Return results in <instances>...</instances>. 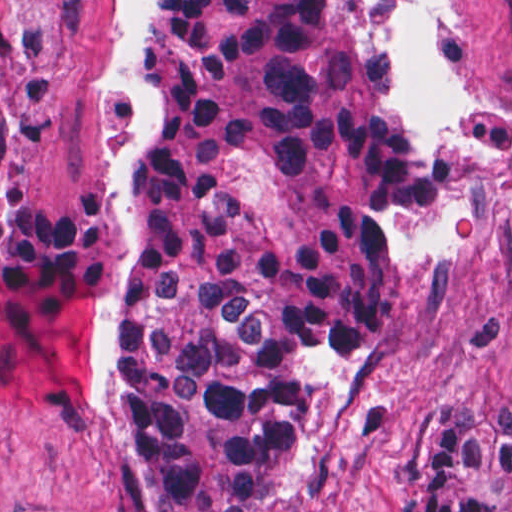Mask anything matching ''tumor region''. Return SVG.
I'll return each mask as SVG.
<instances>
[{
	"instance_id": "e687c5a6",
	"label": "tumor region",
	"mask_w": 512,
	"mask_h": 512,
	"mask_svg": "<svg viewBox=\"0 0 512 512\" xmlns=\"http://www.w3.org/2000/svg\"><path fill=\"white\" fill-rule=\"evenodd\" d=\"M160 127L120 198L136 312L111 433L171 512H268L317 361L399 304L397 224L439 161L391 65V0H151ZM402 512H512V415L425 398Z\"/></svg>"
}]
</instances>
